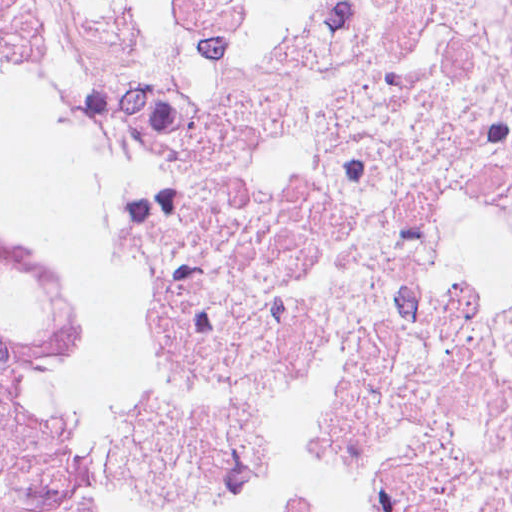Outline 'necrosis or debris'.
Masks as SVG:
<instances>
[{
  "label": "necrosis or debris",
  "mask_w": 512,
  "mask_h": 512,
  "mask_svg": "<svg viewBox=\"0 0 512 512\" xmlns=\"http://www.w3.org/2000/svg\"><path fill=\"white\" fill-rule=\"evenodd\" d=\"M234 329L144 512H512V0H57Z\"/></svg>",
  "instance_id": "1"
}]
</instances>
